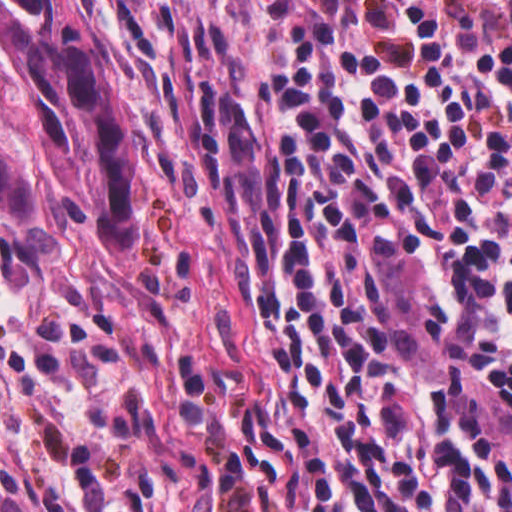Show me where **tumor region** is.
<instances>
[{"label":"tumor region","mask_w":512,"mask_h":512,"mask_svg":"<svg viewBox=\"0 0 512 512\" xmlns=\"http://www.w3.org/2000/svg\"><path fill=\"white\" fill-rule=\"evenodd\" d=\"M0 53L33 110L23 140L0 126V204L31 227L43 214L127 251L139 202L140 114L90 0H0ZM0 512H43L0 480Z\"/></svg>","instance_id":"obj_1"}]
</instances>
